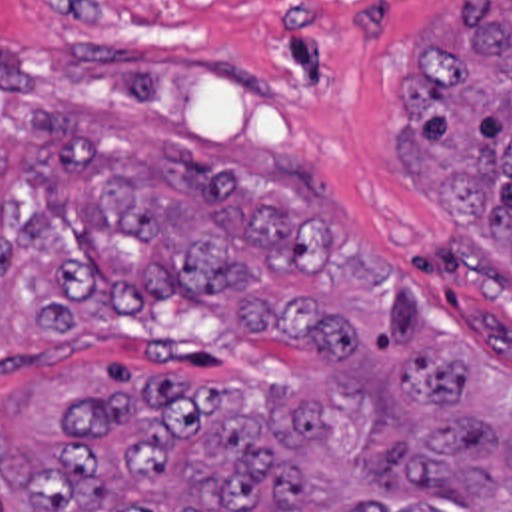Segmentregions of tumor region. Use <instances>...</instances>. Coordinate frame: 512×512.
Listing matches in <instances>:
<instances>
[{"label":"tumor region","instance_id":"obj_1","mask_svg":"<svg viewBox=\"0 0 512 512\" xmlns=\"http://www.w3.org/2000/svg\"><path fill=\"white\" fill-rule=\"evenodd\" d=\"M399 103L417 201L512 261V0L437 25ZM341 209L307 161L225 171L60 109L0 123V339L179 299L299 357L281 397L64 371L0 401V512H512L511 375L431 335Z\"/></svg>","mask_w":512,"mask_h":512}]
</instances>
